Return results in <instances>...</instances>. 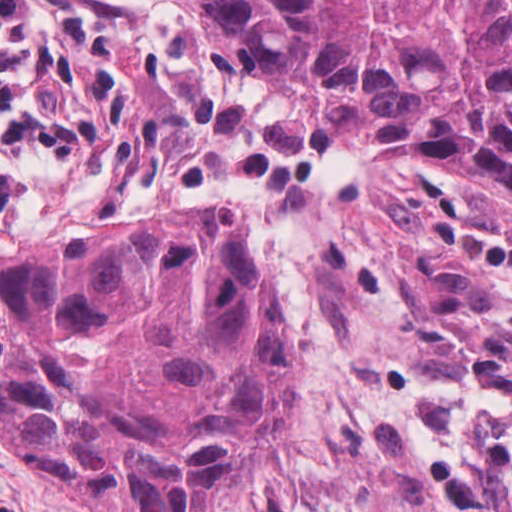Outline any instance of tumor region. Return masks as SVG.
<instances>
[{"label": "tumor region", "mask_w": 512, "mask_h": 512, "mask_svg": "<svg viewBox=\"0 0 512 512\" xmlns=\"http://www.w3.org/2000/svg\"><path fill=\"white\" fill-rule=\"evenodd\" d=\"M365 149L512 205V0H176ZM297 325L237 212L0 259V445L112 512H211L287 426ZM512 502V436L507 440Z\"/></svg>", "instance_id": "obj_1"}]
</instances>
